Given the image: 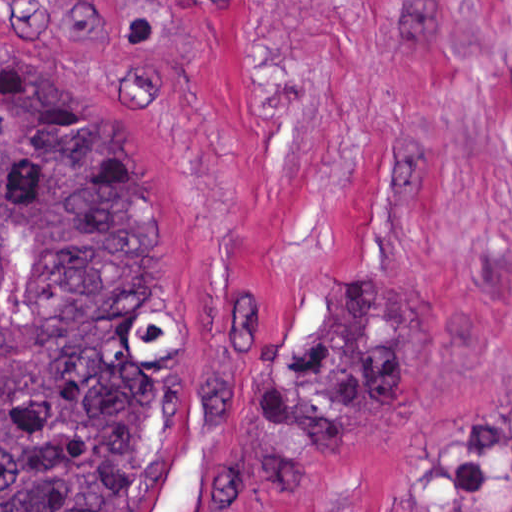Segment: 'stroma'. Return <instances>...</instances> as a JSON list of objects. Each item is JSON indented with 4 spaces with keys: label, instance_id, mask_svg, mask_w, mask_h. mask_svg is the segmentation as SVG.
<instances>
[{
    "label": "stroma",
    "instance_id": "1",
    "mask_svg": "<svg viewBox=\"0 0 512 512\" xmlns=\"http://www.w3.org/2000/svg\"><path fill=\"white\" fill-rule=\"evenodd\" d=\"M0 39L101 86L171 194V478L157 512H512L435 501L428 448L512 404V0H0ZM407 299L398 400L304 474L258 384L345 278Z\"/></svg>",
    "mask_w": 512,
    "mask_h": 512
}]
</instances>
